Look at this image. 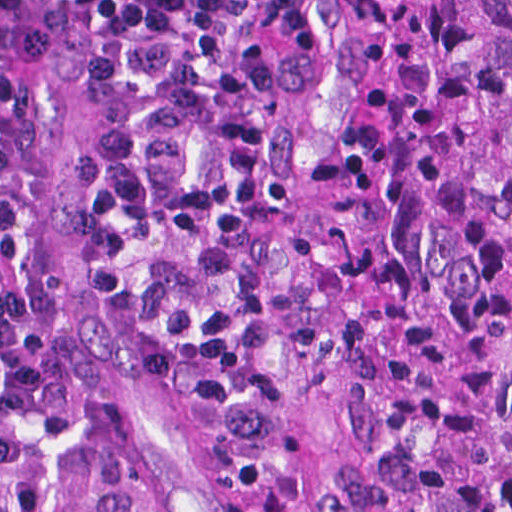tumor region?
Wrapping results in <instances>:
<instances>
[{"mask_svg":"<svg viewBox=\"0 0 512 512\" xmlns=\"http://www.w3.org/2000/svg\"><path fill=\"white\" fill-rule=\"evenodd\" d=\"M412 436L350 512H512V0H307Z\"/></svg>","mask_w":512,"mask_h":512,"instance_id":"obj_1","label":"tumor region"}]
</instances>
